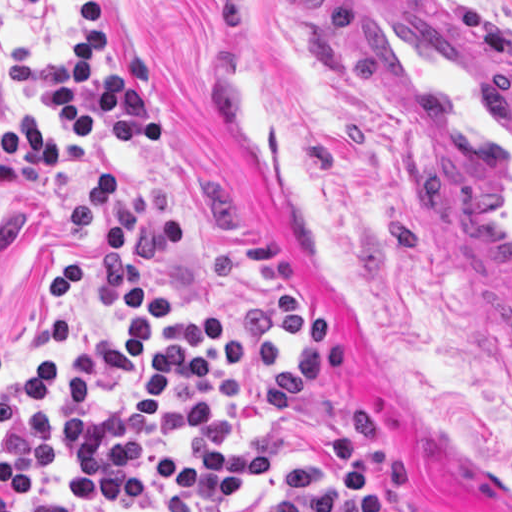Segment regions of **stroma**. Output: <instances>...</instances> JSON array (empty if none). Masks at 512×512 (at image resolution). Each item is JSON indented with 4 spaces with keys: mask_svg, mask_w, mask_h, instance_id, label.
<instances>
[{
    "mask_svg": "<svg viewBox=\"0 0 512 512\" xmlns=\"http://www.w3.org/2000/svg\"><path fill=\"white\" fill-rule=\"evenodd\" d=\"M100 65L154 57L147 96L166 136L123 153L105 140L77 169L158 183L186 224L183 253L138 251L173 314L223 319L231 339L279 354L269 375L176 385L167 418L218 396L169 443L263 449L269 480L205 509L156 478L143 500L88 505L81 472L118 464L132 435L126 385L92 373L85 416L48 402L56 461L28 502L79 512H512V343L474 293L444 226L376 123L348 61L335 0H103ZM512 56V0H434ZM61 25L0 2V127L49 105L9 82L22 44L60 58ZM82 183L35 172L0 193L3 375L36 382L40 353L71 362L121 312L98 245L67 225Z\"/></svg>",
    "mask_w": 512,
    "mask_h": 512,
    "instance_id": "35a3bbf8",
    "label": "stroma"
}]
</instances>
